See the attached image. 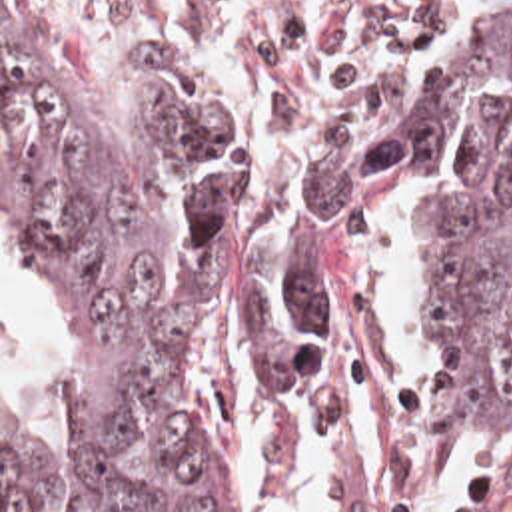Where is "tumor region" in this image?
<instances>
[{
  "label": "tumor region",
  "instance_id": "e687c5a6",
  "mask_svg": "<svg viewBox=\"0 0 512 512\" xmlns=\"http://www.w3.org/2000/svg\"><path fill=\"white\" fill-rule=\"evenodd\" d=\"M387 164L429 178L415 324L477 450L512 430V24L455 42L381 142L357 118L305 142L273 196L214 234L240 174L230 118L170 88L94 104L44 4L0 0V170L84 358L80 512H241L238 466L192 394V338L222 306L269 410H307ZM8 348L0 312V360ZM48 484L40 438L0 424V512H40Z\"/></svg>",
  "mask_w": 512,
  "mask_h": 512
}]
</instances>
